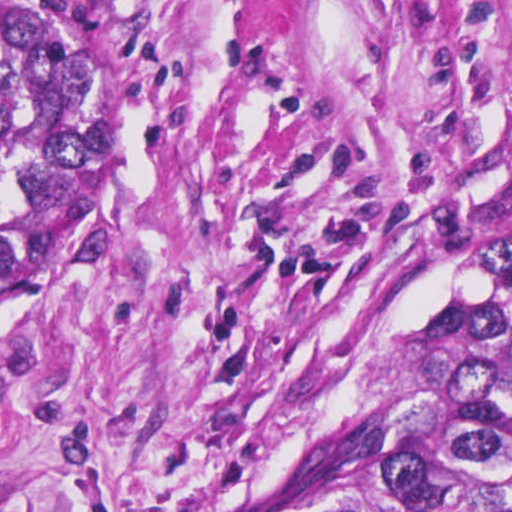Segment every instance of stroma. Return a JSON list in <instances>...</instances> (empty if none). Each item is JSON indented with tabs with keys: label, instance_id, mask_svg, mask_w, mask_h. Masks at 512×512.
I'll list each match as a JSON object with an SVG mask.
<instances>
[{
	"label": "stroma",
	"instance_id": "35a3bbf8",
	"mask_svg": "<svg viewBox=\"0 0 512 512\" xmlns=\"http://www.w3.org/2000/svg\"><path fill=\"white\" fill-rule=\"evenodd\" d=\"M0 306V512H254L459 370L512 252V0H111Z\"/></svg>",
	"mask_w": 512,
	"mask_h": 512
}]
</instances>
